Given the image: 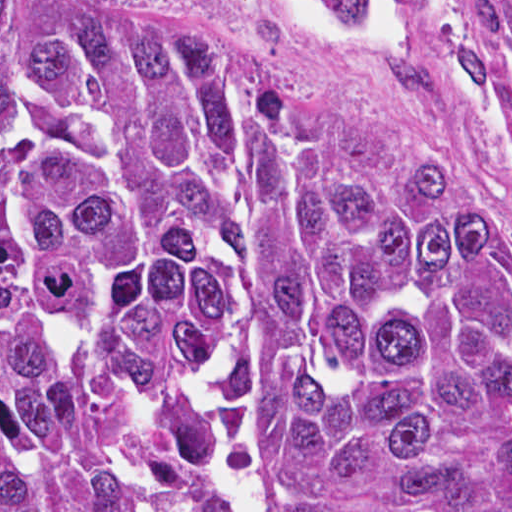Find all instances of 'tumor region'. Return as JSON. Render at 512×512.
Wrapping results in <instances>:
<instances>
[{
    "label": "tumor region",
    "mask_w": 512,
    "mask_h": 512,
    "mask_svg": "<svg viewBox=\"0 0 512 512\" xmlns=\"http://www.w3.org/2000/svg\"><path fill=\"white\" fill-rule=\"evenodd\" d=\"M331 1L512 72V0ZM235 312L257 512H512V242L226 44L0 0V512H223Z\"/></svg>",
    "instance_id": "e687c5a6"
}]
</instances>
